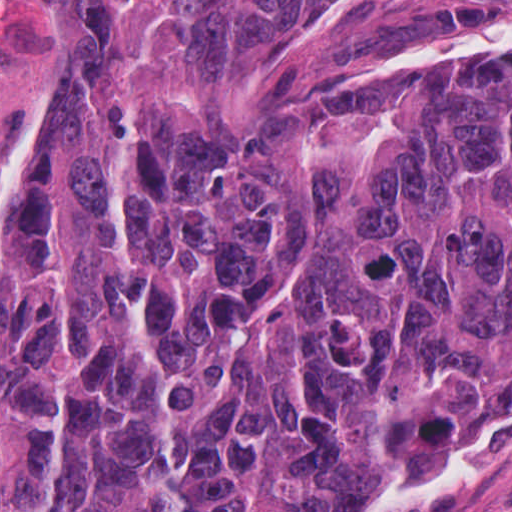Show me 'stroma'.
<instances>
[{
    "label": "stroma",
    "mask_w": 512,
    "mask_h": 512,
    "mask_svg": "<svg viewBox=\"0 0 512 512\" xmlns=\"http://www.w3.org/2000/svg\"><path fill=\"white\" fill-rule=\"evenodd\" d=\"M67 1L176 0H0V244L22 212L35 116L51 83ZM348 512H512V433L454 486L369 498Z\"/></svg>",
    "instance_id": "35a3bbf8"
}]
</instances>
